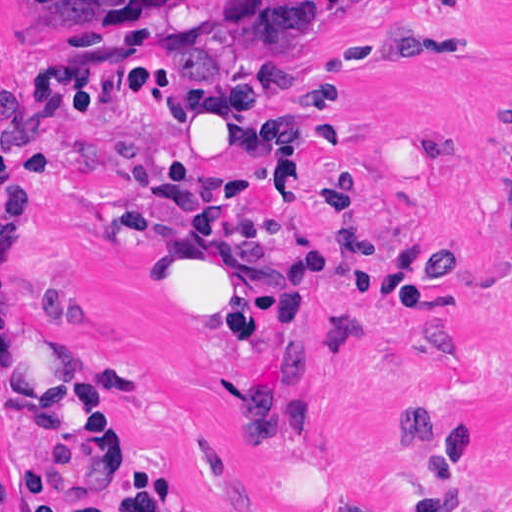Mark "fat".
Returning <instances> with one entry per match:
<instances>
[{"label":"fat","mask_w":512,"mask_h":512,"mask_svg":"<svg viewBox=\"0 0 512 512\" xmlns=\"http://www.w3.org/2000/svg\"><path fill=\"white\" fill-rule=\"evenodd\" d=\"M100 259L112 294L171 318L212 328L256 318L260 250L203 228H165Z\"/></svg>","instance_id":"53f6f03d"}]
</instances>
